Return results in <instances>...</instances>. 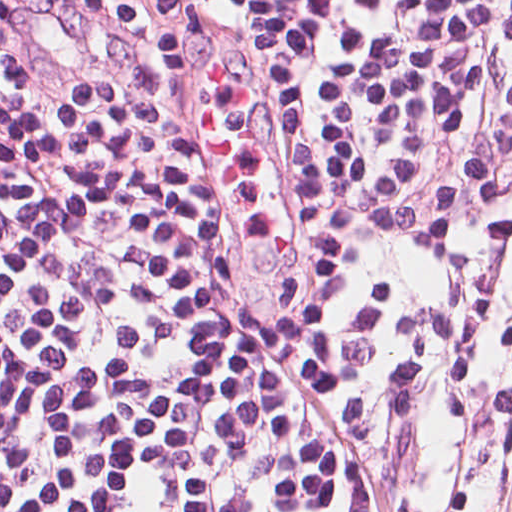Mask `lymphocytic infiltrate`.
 Listing matches in <instances>:
<instances>
[{
  "label": "lymphocytic infiltrate",
  "mask_w": 512,
  "mask_h": 512,
  "mask_svg": "<svg viewBox=\"0 0 512 512\" xmlns=\"http://www.w3.org/2000/svg\"><path fill=\"white\" fill-rule=\"evenodd\" d=\"M512 358V0H0V512H403Z\"/></svg>",
  "instance_id": "obj_1"
}]
</instances>
